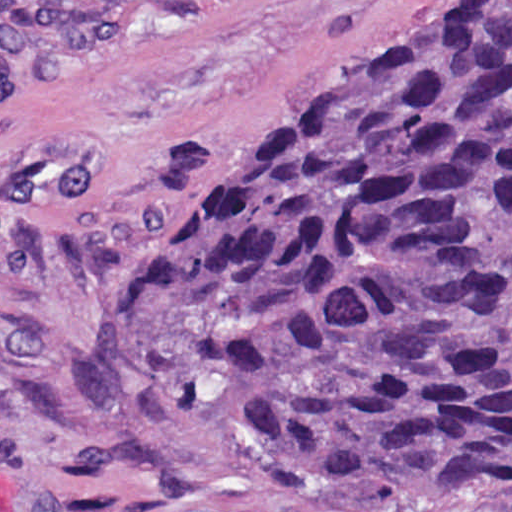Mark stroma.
Wrapping results in <instances>:
<instances>
[{
  "label": "stroma",
  "instance_id": "stroma-1",
  "mask_svg": "<svg viewBox=\"0 0 512 512\" xmlns=\"http://www.w3.org/2000/svg\"><path fill=\"white\" fill-rule=\"evenodd\" d=\"M0 1H127L0 79V512H512L312 488L246 385L150 402L106 349L200 187L438 0Z\"/></svg>",
  "mask_w": 512,
  "mask_h": 512
}]
</instances>
